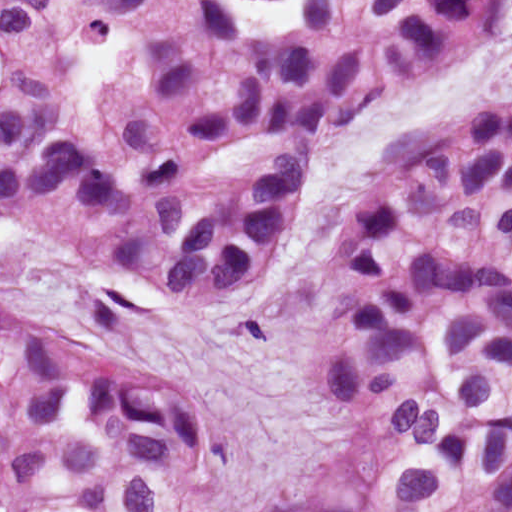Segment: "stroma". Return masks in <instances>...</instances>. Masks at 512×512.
I'll return each instance as SVG.
<instances>
[{"label":"stroma","mask_w":512,"mask_h":512,"mask_svg":"<svg viewBox=\"0 0 512 512\" xmlns=\"http://www.w3.org/2000/svg\"><path fill=\"white\" fill-rule=\"evenodd\" d=\"M512 92V33L437 71L316 162L266 279L238 311L193 317L84 236L10 214L0 238V332L78 340L201 403L218 427L222 508L259 512L351 463V431L322 411L310 374L324 236L365 162L411 120Z\"/></svg>","instance_id":"stroma-1"}]
</instances>
